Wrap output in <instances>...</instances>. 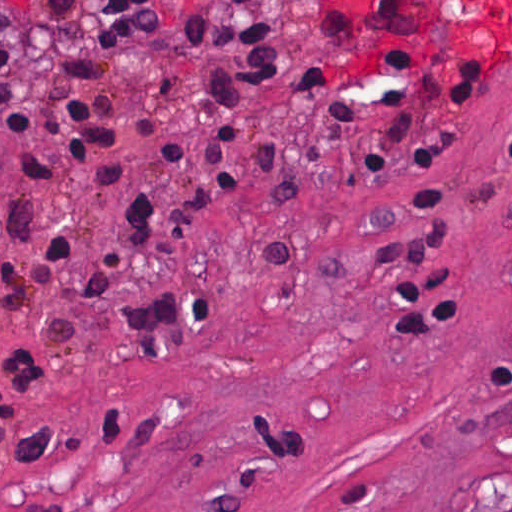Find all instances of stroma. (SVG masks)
Returning a JSON list of instances; mask_svg holds the SVG:
<instances>
[{
	"mask_svg": "<svg viewBox=\"0 0 512 512\" xmlns=\"http://www.w3.org/2000/svg\"><path fill=\"white\" fill-rule=\"evenodd\" d=\"M112 1L50 14L36 0H0V46L14 47L13 92L35 132L0 133V244L33 264L57 232L129 292H207L219 312L147 357L62 285L40 301L72 320L67 338L2 323L0 347L32 349L51 381L0 418V512H512V42L418 35L332 0H155L161 23L125 46L108 87L122 98L123 135L149 114L160 124L117 145L124 175L113 187L63 165L51 188L23 155L55 153L42 133L54 119L51 76L70 54L106 60L98 18ZM186 3L278 18L283 66L250 93L233 193L207 210L186 249L139 256L115 231L116 204L188 183L190 167L155 151L171 136L195 149L206 137V66L181 44ZM374 37L403 62L493 58L474 110L425 124L441 165L375 184L344 165L307 200L274 199L258 142L311 164L360 148L376 125L327 129L323 110L291 93L308 65L328 66L379 120L389 116L375 105L378 87L401 89L425 112L379 62ZM421 182L444 186L446 208L406 224L408 190ZM47 193L35 240L17 241L6 227L14 203ZM286 240L354 252L262 269L261 246ZM428 269L449 271L468 321L456 334L398 335L399 290Z\"/></svg>",
	"mask_w": 512,
	"mask_h": 512,
	"instance_id": "35a3bbf8",
	"label": "stroma"
}]
</instances>
